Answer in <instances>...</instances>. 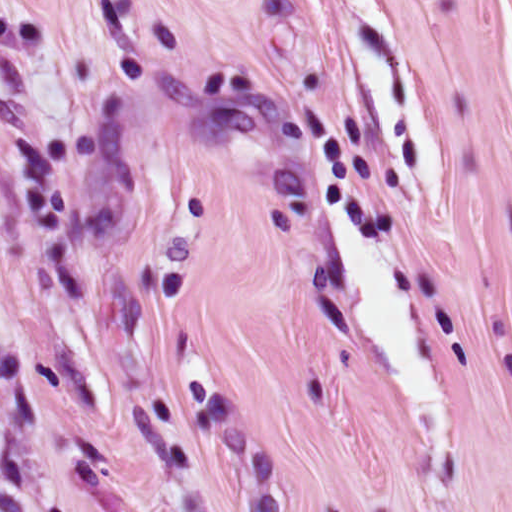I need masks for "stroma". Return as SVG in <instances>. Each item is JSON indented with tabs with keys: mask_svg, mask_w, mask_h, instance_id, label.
<instances>
[{
	"mask_svg": "<svg viewBox=\"0 0 512 512\" xmlns=\"http://www.w3.org/2000/svg\"><path fill=\"white\" fill-rule=\"evenodd\" d=\"M370 1L441 210L351 0H0V512H512V0Z\"/></svg>",
	"mask_w": 512,
	"mask_h": 512,
	"instance_id": "35a3bbf8",
	"label": "stroma"
}]
</instances>
